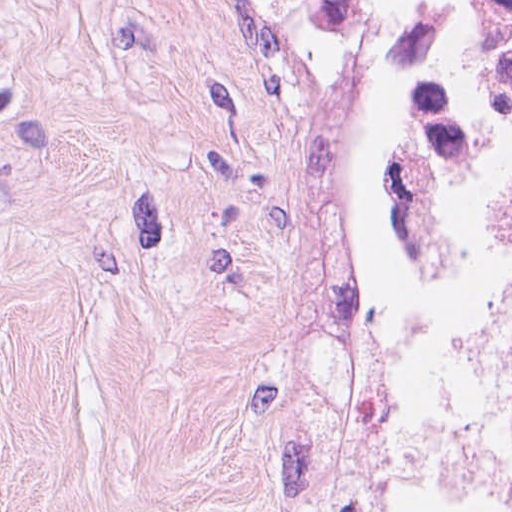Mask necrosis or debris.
Listing matches in <instances>:
<instances>
[{"instance_id": "1", "label": "necrosis or debris", "mask_w": 512, "mask_h": 512, "mask_svg": "<svg viewBox=\"0 0 512 512\" xmlns=\"http://www.w3.org/2000/svg\"><path fill=\"white\" fill-rule=\"evenodd\" d=\"M480 141L512 249V0L451 1L407 26L389 103L387 244L399 261L434 250L451 183Z\"/></svg>"}]
</instances>
